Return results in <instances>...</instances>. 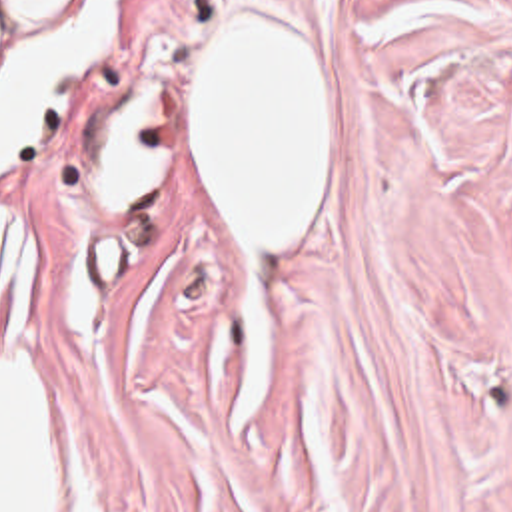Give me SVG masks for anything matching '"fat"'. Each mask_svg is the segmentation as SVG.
I'll return each instance as SVG.
<instances>
[{
  "label": "fat",
  "mask_w": 512,
  "mask_h": 512,
  "mask_svg": "<svg viewBox=\"0 0 512 512\" xmlns=\"http://www.w3.org/2000/svg\"><path fill=\"white\" fill-rule=\"evenodd\" d=\"M118 0H0V177L36 147L96 65ZM34 261L0 211V512H62V421L14 341Z\"/></svg>",
  "instance_id": "1"
}]
</instances>
